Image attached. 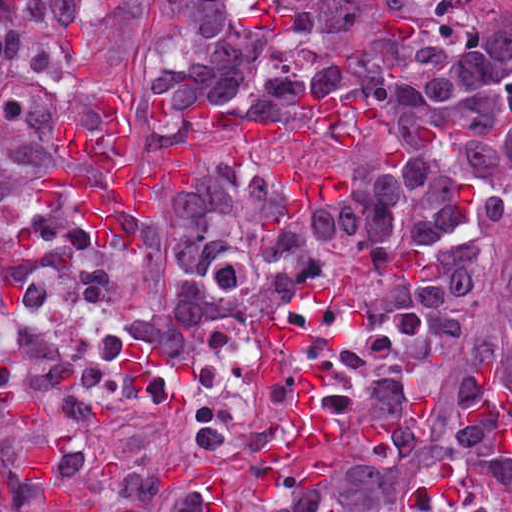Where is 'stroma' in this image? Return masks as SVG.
<instances>
[{
	"instance_id": "stroma-1",
	"label": "stroma",
	"mask_w": 512,
	"mask_h": 512,
	"mask_svg": "<svg viewBox=\"0 0 512 512\" xmlns=\"http://www.w3.org/2000/svg\"><path fill=\"white\" fill-rule=\"evenodd\" d=\"M477 26L512 27V0H479ZM104 99L90 98L73 111L95 133L108 130ZM118 99L131 125L130 157L144 175L165 165L144 115ZM194 194L185 183L170 181L159 215ZM510 250L512 217L490 222L477 235H457L428 246H378L361 238L322 235L259 280L217 285L222 317L205 323L187 350L178 354L205 343L211 325L227 315H266L282 306L301 275H319L344 318L342 308L352 321ZM130 267L184 276L166 259ZM36 272L91 279L107 288L116 301L105 266L81 262L62 239H48L33 242L0 262V312L19 305L23 289ZM150 410L130 400H106L83 387L76 380L73 343L36 347L0 367V477Z\"/></svg>"
}]
</instances>
